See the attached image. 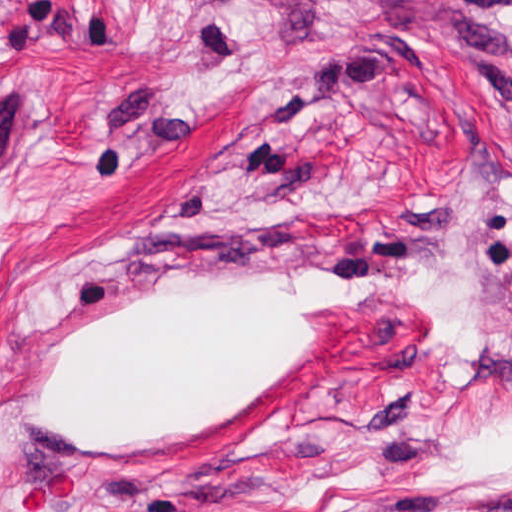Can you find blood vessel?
I'll return each instance as SVG.
<instances>
[{
    "label": "blood vessel",
    "mask_w": 512,
    "mask_h": 512,
    "mask_svg": "<svg viewBox=\"0 0 512 512\" xmlns=\"http://www.w3.org/2000/svg\"><path fill=\"white\" fill-rule=\"evenodd\" d=\"M26 112L32 102L22 84L9 74L0 76V172L19 147Z\"/></svg>",
    "instance_id": "8fb6f2fc"
}]
</instances>
